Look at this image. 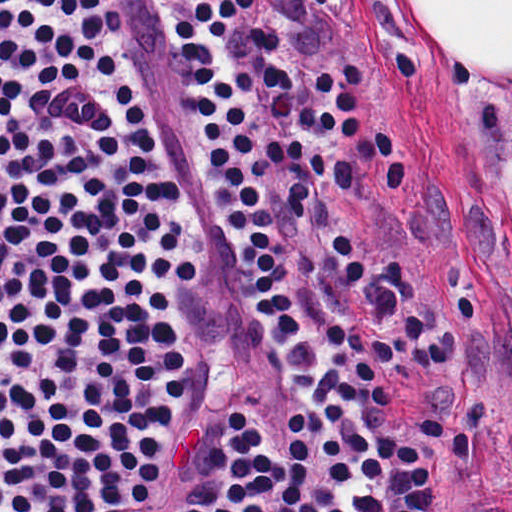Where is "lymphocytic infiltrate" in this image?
I'll return each mask as SVG.
<instances>
[{
  "mask_svg": "<svg viewBox=\"0 0 512 512\" xmlns=\"http://www.w3.org/2000/svg\"><path fill=\"white\" fill-rule=\"evenodd\" d=\"M180 1L172 39L214 204L253 312L324 419V512H437L419 446L389 424V396L445 372L448 350L404 263H384L337 197L368 164L386 192L406 185L390 135L363 134L366 70L316 72L299 111L261 0ZM180 197L150 0H0V512H316L302 404L274 475L277 413L226 404L216 430L197 422L169 297L70 252L100 246L125 271L196 286ZM215 432L255 451L223 455L177 499Z\"/></svg>",
  "mask_w": 512,
  "mask_h": 512,
  "instance_id": "lymphocytic-infiltrate-1",
  "label": "lymphocytic infiltrate"
}]
</instances>
